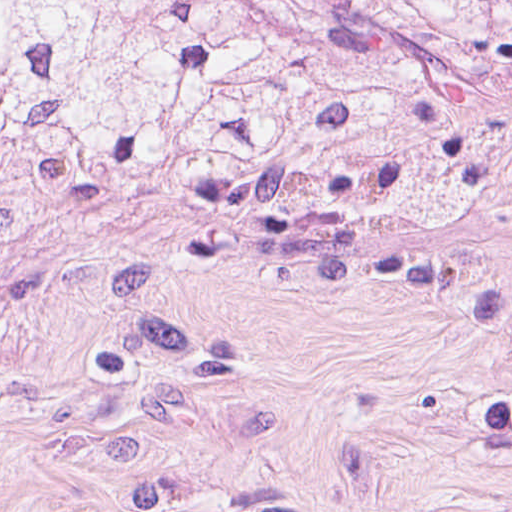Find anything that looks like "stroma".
<instances>
[{
	"instance_id": "obj_1",
	"label": "stroma",
	"mask_w": 512,
	"mask_h": 512,
	"mask_svg": "<svg viewBox=\"0 0 512 512\" xmlns=\"http://www.w3.org/2000/svg\"><path fill=\"white\" fill-rule=\"evenodd\" d=\"M0 512H512V242L331 263L145 209L0 241Z\"/></svg>"
}]
</instances>
